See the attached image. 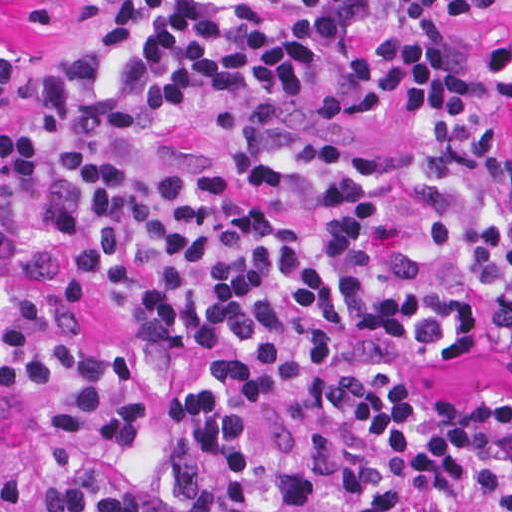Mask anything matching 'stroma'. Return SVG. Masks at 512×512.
<instances>
[{"mask_svg":"<svg viewBox=\"0 0 512 512\" xmlns=\"http://www.w3.org/2000/svg\"><path fill=\"white\" fill-rule=\"evenodd\" d=\"M112 2L0 0V45L37 51L65 41L119 16ZM462 300L469 321V346L463 352L417 357L389 339L381 348L441 398H471L487 390H512V348H490L494 314L487 300L470 286ZM80 316L85 328L110 349L138 353L140 336L125 317L117 289L98 279Z\"/></svg>","mask_w":512,"mask_h":512,"instance_id":"obj_1","label":"stroma"}]
</instances>
